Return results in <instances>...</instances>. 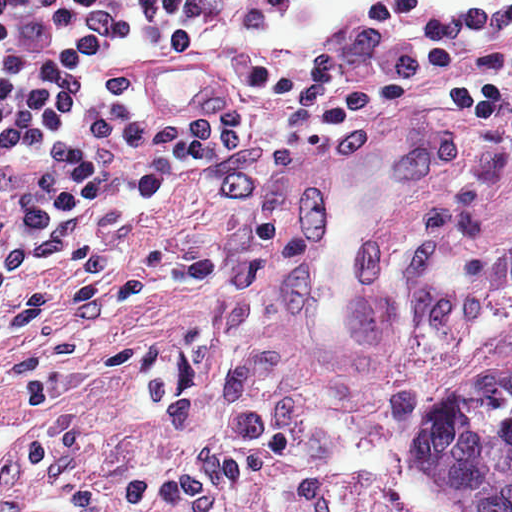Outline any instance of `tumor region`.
Instances as JSON below:
<instances>
[{
  "mask_svg": "<svg viewBox=\"0 0 512 512\" xmlns=\"http://www.w3.org/2000/svg\"><path fill=\"white\" fill-rule=\"evenodd\" d=\"M484 370L425 409L419 465L452 512H512V364Z\"/></svg>",
  "mask_w": 512,
  "mask_h": 512,
  "instance_id": "e687c5a6",
  "label": "tumor region"
}]
</instances>
